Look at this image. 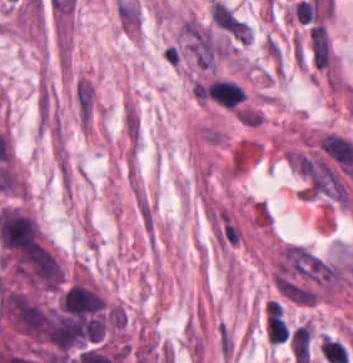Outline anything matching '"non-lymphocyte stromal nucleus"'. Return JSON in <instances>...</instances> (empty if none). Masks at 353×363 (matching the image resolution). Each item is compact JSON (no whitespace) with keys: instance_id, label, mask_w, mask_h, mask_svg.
I'll list each match as a JSON object with an SVG mask.
<instances>
[{"instance_id":"1","label":"non-lymphocyte stromal nucleus","mask_w":353,"mask_h":363,"mask_svg":"<svg viewBox=\"0 0 353 363\" xmlns=\"http://www.w3.org/2000/svg\"><path fill=\"white\" fill-rule=\"evenodd\" d=\"M308 40L316 66L326 68L331 64L329 37L322 24L308 29Z\"/></svg>"},{"instance_id":"2","label":"non-lymphocyte stromal nucleus","mask_w":353,"mask_h":363,"mask_svg":"<svg viewBox=\"0 0 353 363\" xmlns=\"http://www.w3.org/2000/svg\"><path fill=\"white\" fill-rule=\"evenodd\" d=\"M216 334L219 354L223 362L229 363L234 350V336L228 323L221 319L216 326Z\"/></svg>"},{"instance_id":"3","label":"non-lymphocyte stromal nucleus","mask_w":353,"mask_h":363,"mask_svg":"<svg viewBox=\"0 0 353 363\" xmlns=\"http://www.w3.org/2000/svg\"><path fill=\"white\" fill-rule=\"evenodd\" d=\"M135 205L143 230L147 237L151 239L154 227V218L151 206L140 192L135 195Z\"/></svg>"}]
</instances>
